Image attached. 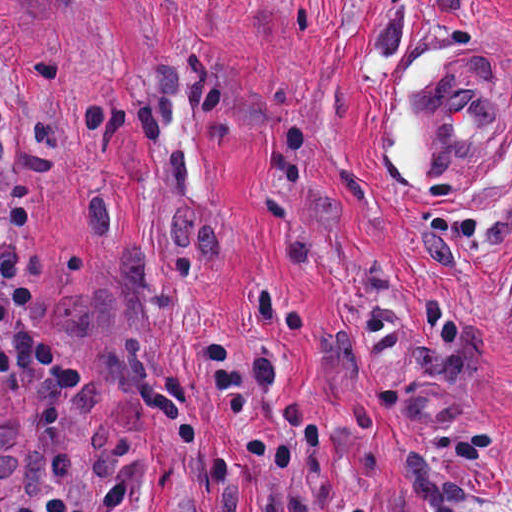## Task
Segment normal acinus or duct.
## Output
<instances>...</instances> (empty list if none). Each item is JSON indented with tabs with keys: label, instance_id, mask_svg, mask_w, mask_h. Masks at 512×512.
I'll return each mask as SVG.
<instances>
[{
	"label": "normal acinus or duct",
	"instance_id": "30e58d81",
	"mask_svg": "<svg viewBox=\"0 0 512 512\" xmlns=\"http://www.w3.org/2000/svg\"><path fill=\"white\" fill-rule=\"evenodd\" d=\"M30 465V439L17 405L0 386V503Z\"/></svg>",
	"mask_w": 512,
	"mask_h": 512
}]
</instances>
